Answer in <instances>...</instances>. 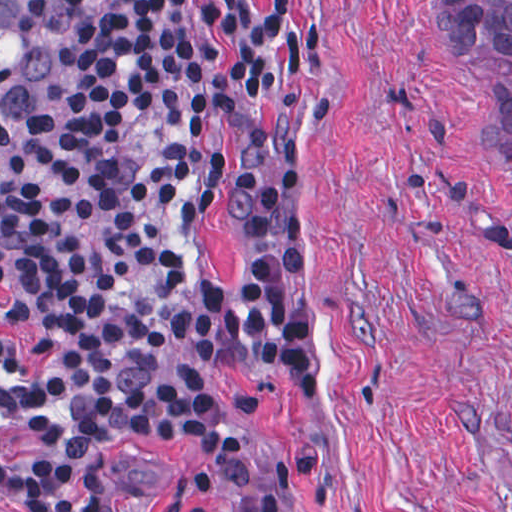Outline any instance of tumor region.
Masks as SVG:
<instances>
[{
  "mask_svg": "<svg viewBox=\"0 0 512 512\" xmlns=\"http://www.w3.org/2000/svg\"><path fill=\"white\" fill-rule=\"evenodd\" d=\"M453 63L512 69V0H441ZM67 20L43 0H0V143L53 99ZM502 154L512 166V88L490 82Z\"/></svg>",
  "mask_w": 512,
  "mask_h": 512,
  "instance_id": "obj_1",
  "label": "tumor region"
}]
</instances>
